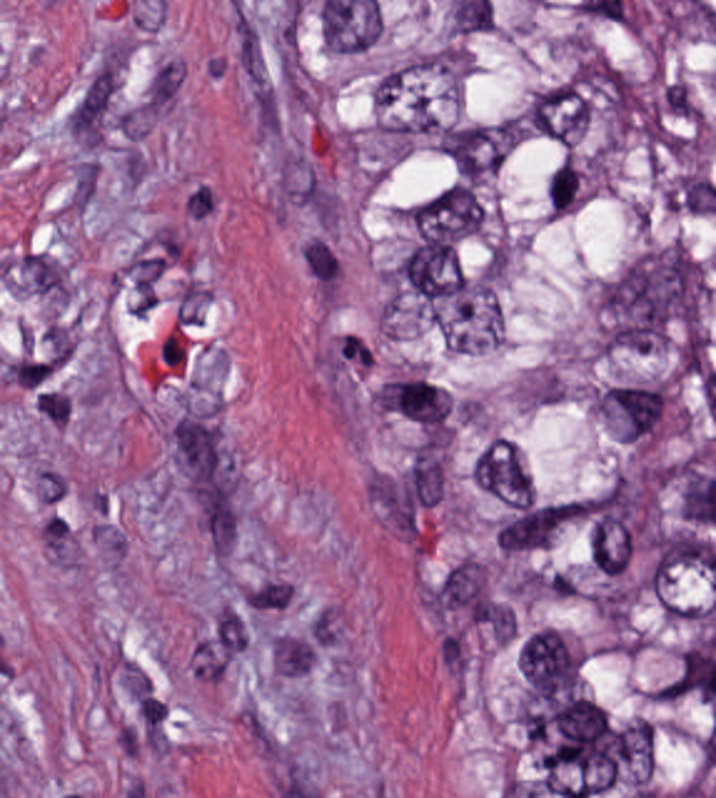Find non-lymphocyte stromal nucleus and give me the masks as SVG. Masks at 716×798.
<instances>
[{"label": "non-lymphocyte stromal nucleus", "mask_w": 716, "mask_h": 798, "mask_svg": "<svg viewBox=\"0 0 716 798\" xmlns=\"http://www.w3.org/2000/svg\"><path fill=\"white\" fill-rule=\"evenodd\" d=\"M226 123H277V2H226Z\"/></svg>", "instance_id": "1"}, {"label": "non-lymphocyte stromal nucleus", "mask_w": 716, "mask_h": 798, "mask_svg": "<svg viewBox=\"0 0 716 798\" xmlns=\"http://www.w3.org/2000/svg\"><path fill=\"white\" fill-rule=\"evenodd\" d=\"M64 137H125V62H64Z\"/></svg>", "instance_id": "2"}, {"label": "non-lymphocyte stromal nucleus", "mask_w": 716, "mask_h": 798, "mask_svg": "<svg viewBox=\"0 0 716 798\" xmlns=\"http://www.w3.org/2000/svg\"><path fill=\"white\" fill-rule=\"evenodd\" d=\"M189 420H225V334H189Z\"/></svg>", "instance_id": "3"}, {"label": "non-lymphocyte stromal nucleus", "mask_w": 716, "mask_h": 798, "mask_svg": "<svg viewBox=\"0 0 716 798\" xmlns=\"http://www.w3.org/2000/svg\"><path fill=\"white\" fill-rule=\"evenodd\" d=\"M234 612H295V571H234Z\"/></svg>", "instance_id": "4"}, {"label": "non-lymphocyte stromal nucleus", "mask_w": 716, "mask_h": 798, "mask_svg": "<svg viewBox=\"0 0 716 798\" xmlns=\"http://www.w3.org/2000/svg\"><path fill=\"white\" fill-rule=\"evenodd\" d=\"M2 297H63V256H2Z\"/></svg>", "instance_id": "5"}, {"label": "non-lymphocyte stromal nucleus", "mask_w": 716, "mask_h": 798, "mask_svg": "<svg viewBox=\"0 0 716 798\" xmlns=\"http://www.w3.org/2000/svg\"><path fill=\"white\" fill-rule=\"evenodd\" d=\"M443 609H489V558H443Z\"/></svg>", "instance_id": "6"}, {"label": "non-lymphocyte stromal nucleus", "mask_w": 716, "mask_h": 798, "mask_svg": "<svg viewBox=\"0 0 716 798\" xmlns=\"http://www.w3.org/2000/svg\"><path fill=\"white\" fill-rule=\"evenodd\" d=\"M411 504H447V439H411Z\"/></svg>", "instance_id": "7"}, {"label": "non-lymphocyte stromal nucleus", "mask_w": 716, "mask_h": 798, "mask_svg": "<svg viewBox=\"0 0 716 798\" xmlns=\"http://www.w3.org/2000/svg\"><path fill=\"white\" fill-rule=\"evenodd\" d=\"M174 479H210V414H174Z\"/></svg>", "instance_id": "8"}, {"label": "non-lymphocyte stromal nucleus", "mask_w": 716, "mask_h": 798, "mask_svg": "<svg viewBox=\"0 0 716 798\" xmlns=\"http://www.w3.org/2000/svg\"><path fill=\"white\" fill-rule=\"evenodd\" d=\"M434 674H479V628H434Z\"/></svg>", "instance_id": "9"}, {"label": "non-lymphocyte stromal nucleus", "mask_w": 716, "mask_h": 798, "mask_svg": "<svg viewBox=\"0 0 716 798\" xmlns=\"http://www.w3.org/2000/svg\"><path fill=\"white\" fill-rule=\"evenodd\" d=\"M151 108H187V52H151Z\"/></svg>", "instance_id": "10"}, {"label": "non-lymphocyte stromal nucleus", "mask_w": 716, "mask_h": 798, "mask_svg": "<svg viewBox=\"0 0 716 798\" xmlns=\"http://www.w3.org/2000/svg\"><path fill=\"white\" fill-rule=\"evenodd\" d=\"M204 554H240V498H204Z\"/></svg>", "instance_id": "11"}, {"label": "non-lymphocyte stromal nucleus", "mask_w": 716, "mask_h": 798, "mask_svg": "<svg viewBox=\"0 0 716 798\" xmlns=\"http://www.w3.org/2000/svg\"><path fill=\"white\" fill-rule=\"evenodd\" d=\"M206 489H247V443H206Z\"/></svg>", "instance_id": "12"}, {"label": "non-lymphocyte stromal nucleus", "mask_w": 716, "mask_h": 798, "mask_svg": "<svg viewBox=\"0 0 716 798\" xmlns=\"http://www.w3.org/2000/svg\"><path fill=\"white\" fill-rule=\"evenodd\" d=\"M109 287H160V251H109Z\"/></svg>", "instance_id": "13"}, {"label": "non-lymphocyte stromal nucleus", "mask_w": 716, "mask_h": 798, "mask_svg": "<svg viewBox=\"0 0 716 798\" xmlns=\"http://www.w3.org/2000/svg\"><path fill=\"white\" fill-rule=\"evenodd\" d=\"M486 647H522V601H486Z\"/></svg>", "instance_id": "14"}]
</instances>
